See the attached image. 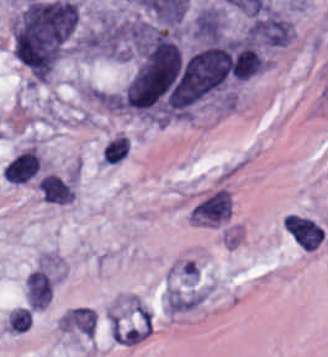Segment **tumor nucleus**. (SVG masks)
Here are the masks:
<instances>
[{
	"label": "tumor nucleus",
	"instance_id": "2f306a5c",
	"mask_svg": "<svg viewBox=\"0 0 328 357\" xmlns=\"http://www.w3.org/2000/svg\"><path fill=\"white\" fill-rule=\"evenodd\" d=\"M78 24L79 12L27 2L11 20L12 50L28 71L54 68Z\"/></svg>",
	"mask_w": 328,
	"mask_h": 357
}]
</instances>
